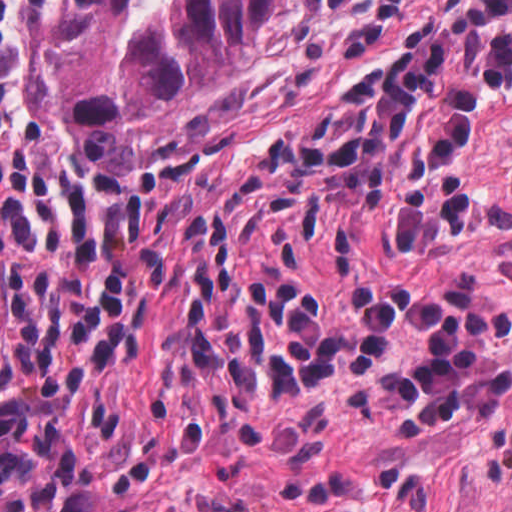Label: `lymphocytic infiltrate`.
Returning <instances> with one entry per match:
<instances>
[{
  "mask_svg": "<svg viewBox=\"0 0 512 512\" xmlns=\"http://www.w3.org/2000/svg\"><path fill=\"white\" fill-rule=\"evenodd\" d=\"M54 1L0 0V235L78 190L24 159L19 140L23 26Z\"/></svg>",
  "mask_w": 512,
  "mask_h": 512,
  "instance_id": "lymphocytic-infiltrate-1",
  "label": "lymphocytic infiltrate"
}]
</instances>
